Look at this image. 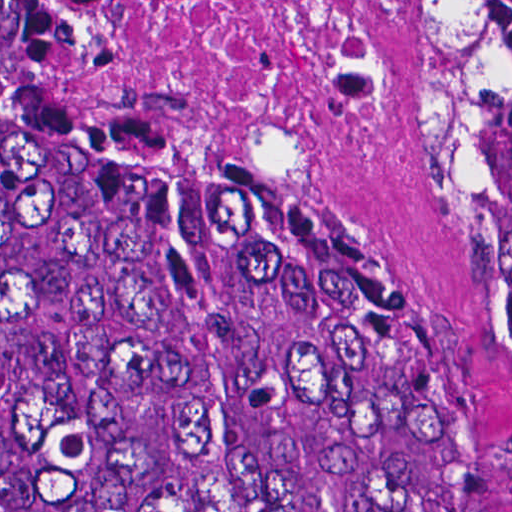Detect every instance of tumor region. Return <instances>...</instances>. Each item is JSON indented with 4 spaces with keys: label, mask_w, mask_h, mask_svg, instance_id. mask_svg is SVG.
I'll return each instance as SVG.
<instances>
[{
    "label": "tumor region",
    "mask_w": 512,
    "mask_h": 512,
    "mask_svg": "<svg viewBox=\"0 0 512 512\" xmlns=\"http://www.w3.org/2000/svg\"><path fill=\"white\" fill-rule=\"evenodd\" d=\"M413 154L489 195L512 309V0H409ZM304 165L56 142L0 0V512H485Z\"/></svg>",
    "instance_id": "e687c5a6"
}]
</instances>
